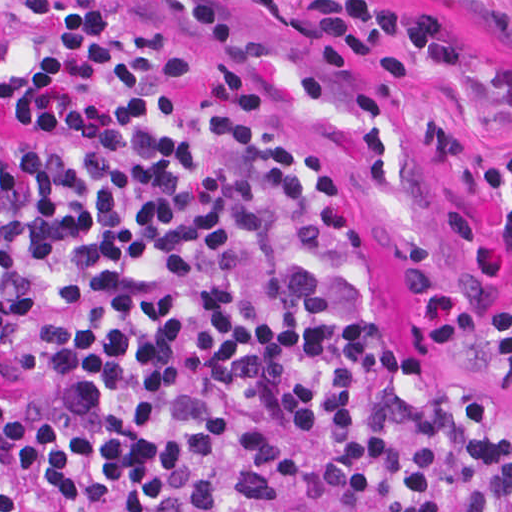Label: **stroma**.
I'll use <instances>...</instances> for the list:
<instances>
[{"mask_svg":"<svg viewBox=\"0 0 512 512\" xmlns=\"http://www.w3.org/2000/svg\"><path fill=\"white\" fill-rule=\"evenodd\" d=\"M286 60L291 110L336 167L392 223L397 275L392 320H421L507 279V251L471 182L438 142L442 119L461 102L512 107V0H390L441 9L456 19L463 60L419 66L390 87L358 64L353 82L316 66L283 32L299 0H243ZM403 346L445 388L479 395L512 416V370L495 341H462L403 326ZM21 376L0 348V390Z\"/></svg>","mask_w":512,"mask_h":512,"instance_id":"stroma-1","label":"stroma"}]
</instances>
